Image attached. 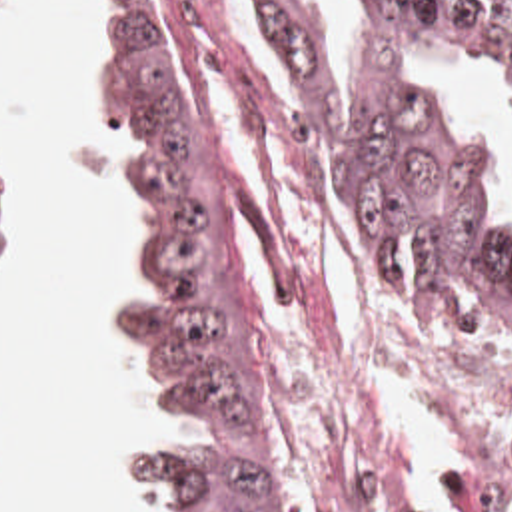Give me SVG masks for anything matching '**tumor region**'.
Segmentation results:
<instances>
[{"label":"tumor region","instance_id":"e687c5a6","mask_svg":"<svg viewBox=\"0 0 512 512\" xmlns=\"http://www.w3.org/2000/svg\"><path fill=\"white\" fill-rule=\"evenodd\" d=\"M304 81L306 109H270L362 251L446 319L512 333V243L490 223L404 45H462L512 73V0H366L364 77L342 107L310 0H262ZM94 119L136 139L130 277L108 303L152 381L162 432L122 470L178 512H284L264 363L220 235L188 87L152 0H102ZM476 512L512 506V426L466 460Z\"/></svg>","mask_w":512,"mask_h":512}]
</instances>
